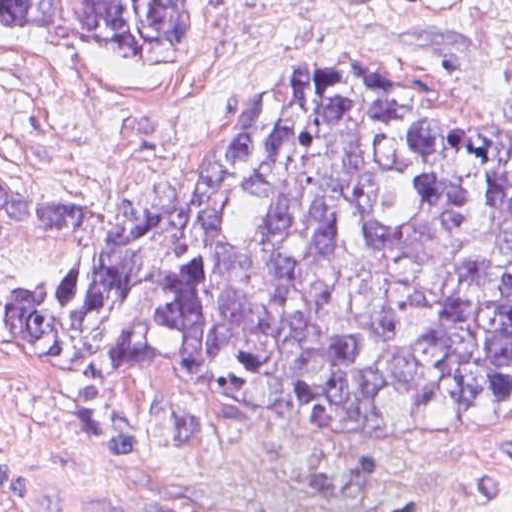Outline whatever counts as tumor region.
I'll return each mask as SVG.
<instances>
[{"label": "tumor region", "mask_w": 512, "mask_h": 512, "mask_svg": "<svg viewBox=\"0 0 512 512\" xmlns=\"http://www.w3.org/2000/svg\"><path fill=\"white\" fill-rule=\"evenodd\" d=\"M0 22L189 62L190 0H0ZM0 224L85 244L9 288L42 370L170 362L232 417L328 439L512 408V136L374 75H297L117 215L0 170Z\"/></svg>", "instance_id": "tumor-region-1"}]
</instances>
